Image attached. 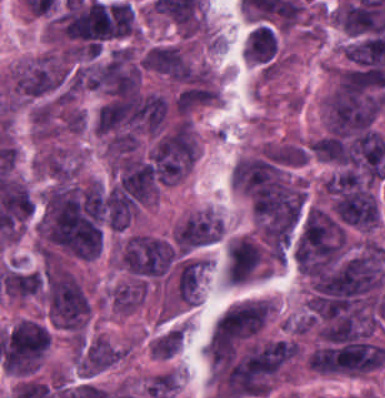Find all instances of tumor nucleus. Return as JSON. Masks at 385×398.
Listing matches in <instances>:
<instances>
[{"instance_id":"3","label":"tumor nucleus","mask_w":385,"mask_h":398,"mask_svg":"<svg viewBox=\"0 0 385 398\" xmlns=\"http://www.w3.org/2000/svg\"><path fill=\"white\" fill-rule=\"evenodd\" d=\"M139 68L128 49L117 48L95 62L84 75V87L109 92L137 89Z\"/></svg>"},{"instance_id":"8","label":"tumor nucleus","mask_w":385,"mask_h":398,"mask_svg":"<svg viewBox=\"0 0 385 398\" xmlns=\"http://www.w3.org/2000/svg\"><path fill=\"white\" fill-rule=\"evenodd\" d=\"M142 67L176 80L188 78V61L184 52L169 43L148 48L142 57Z\"/></svg>"},{"instance_id":"7","label":"tumor nucleus","mask_w":385,"mask_h":398,"mask_svg":"<svg viewBox=\"0 0 385 398\" xmlns=\"http://www.w3.org/2000/svg\"><path fill=\"white\" fill-rule=\"evenodd\" d=\"M323 122L328 132L349 133L365 128L375 115L328 95L322 97Z\"/></svg>"},{"instance_id":"10","label":"tumor nucleus","mask_w":385,"mask_h":398,"mask_svg":"<svg viewBox=\"0 0 385 398\" xmlns=\"http://www.w3.org/2000/svg\"><path fill=\"white\" fill-rule=\"evenodd\" d=\"M38 168L55 179L74 176L76 166L61 148H54L40 157Z\"/></svg>"},{"instance_id":"1","label":"tumor nucleus","mask_w":385,"mask_h":398,"mask_svg":"<svg viewBox=\"0 0 385 398\" xmlns=\"http://www.w3.org/2000/svg\"><path fill=\"white\" fill-rule=\"evenodd\" d=\"M45 299L50 321L63 330H83L89 317V299L71 272L56 266L47 267Z\"/></svg>"},{"instance_id":"4","label":"tumor nucleus","mask_w":385,"mask_h":398,"mask_svg":"<svg viewBox=\"0 0 385 398\" xmlns=\"http://www.w3.org/2000/svg\"><path fill=\"white\" fill-rule=\"evenodd\" d=\"M272 306L267 300L247 301L226 310L213 325V345L253 336L263 328Z\"/></svg>"},{"instance_id":"6","label":"tumor nucleus","mask_w":385,"mask_h":398,"mask_svg":"<svg viewBox=\"0 0 385 398\" xmlns=\"http://www.w3.org/2000/svg\"><path fill=\"white\" fill-rule=\"evenodd\" d=\"M348 224L361 230H371L380 218L376 199L367 188L342 192L333 206Z\"/></svg>"},{"instance_id":"9","label":"tumor nucleus","mask_w":385,"mask_h":398,"mask_svg":"<svg viewBox=\"0 0 385 398\" xmlns=\"http://www.w3.org/2000/svg\"><path fill=\"white\" fill-rule=\"evenodd\" d=\"M43 277L39 271L5 266L3 272V295L27 299L41 295Z\"/></svg>"},{"instance_id":"5","label":"tumor nucleus","mask_w":385,"mask_h":398,"mask_svg":"<svg viewBox=\"0 0 385 398\" xmlns=\"http://www.w3.org/2000/svg\"><path fill=\"white\" fill-rule=\"evenodd\" d=\"M172 254L170 245L163 240L133 235L127 237L122 245L118 263L133 272L163 273Z\"/></svg>"},{"instance_id":"2","label":"tumor nucleus","mask_w":385,"mask_h":398,"mask_svg":"<svg viewBox=\"0 0 385 398\" xmlns=\"http://www.w3.org/2000/svg\"><path fill=\"white\" fill-rule=\"evenodd\" d=\"M67 76L68 67L63 58L43 54L15 71L10 89L15 97L33 101L61 89Z\"/></svg>"}]
</instances>
